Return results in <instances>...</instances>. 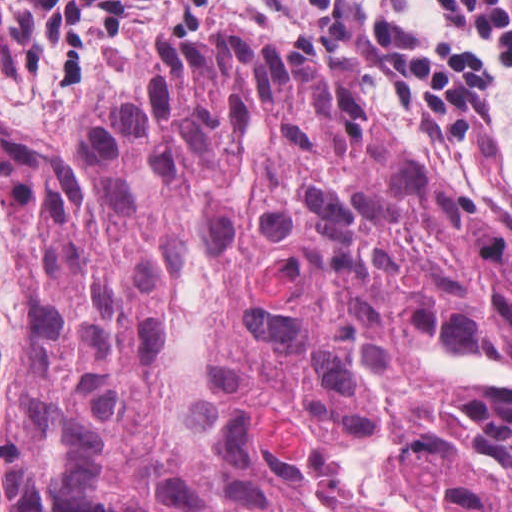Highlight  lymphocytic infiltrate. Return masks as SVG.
<instances>
[{"label": "lymphocytic infiltrate", "instance_id": "obj_1", "mask_svg": "<svg viewBox=\"0 0 512 512\" xmlns=\"http://www.w3.org/2000/svg\"><path fill=\"white\" fill-rule=\"evenodd\" d=\"M190 5L294 30L386 104L431 116L488 171L512 174V0H0V105L55 118L119 72L136 32Z\"/></svg>", "mask_w": 512, "mask_h": 512}]
</instances>
